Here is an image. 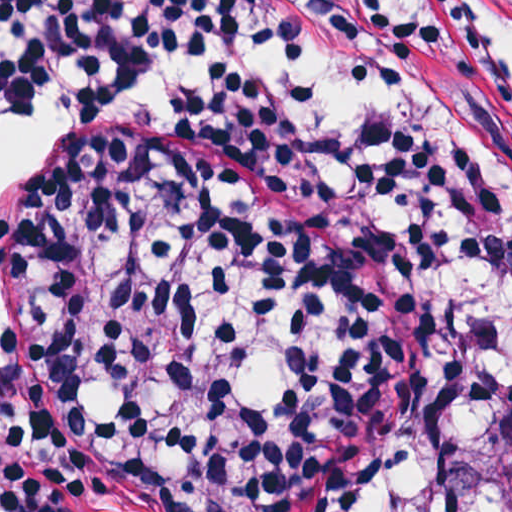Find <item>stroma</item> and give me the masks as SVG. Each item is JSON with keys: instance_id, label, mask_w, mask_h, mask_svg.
<instances>
[{"instance_id": "obj_1", "label": "stroma", "mask_w": 512, "mask_h": 512, "mask_svg": "<svg viewBox=\"0 0 512 512\" xmlns=\"http://www.w3.org/2000/svg\"><path fill=\"white\" fill-rule=\"evenodd\" d=\"M389 105L512 182V71L472 0H311ZM436 299L345 257L276 157L93 110L0 251V364L131 512H339L376 478Z\"/></svg>"}]
</instances>
